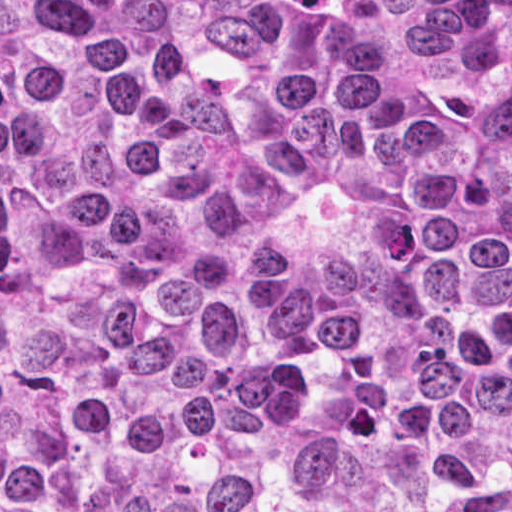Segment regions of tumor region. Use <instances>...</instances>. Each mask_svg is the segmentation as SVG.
Here are the masks:
<instances>
[{
    "instance_id": "1",
    "label": "tumor region",
    "mask_w": 512,
    "mask_h": 512,
    "mask_svg": "<svg viewBox=\"0 0 512 512\" xmlns=\"http://www.w3.org/2000/svg\"><path fill=\"white\" fill-rule=\"evenodd\" d=\"M0 512H512V0H0Z\"/></svg>"
}]
</instances>
